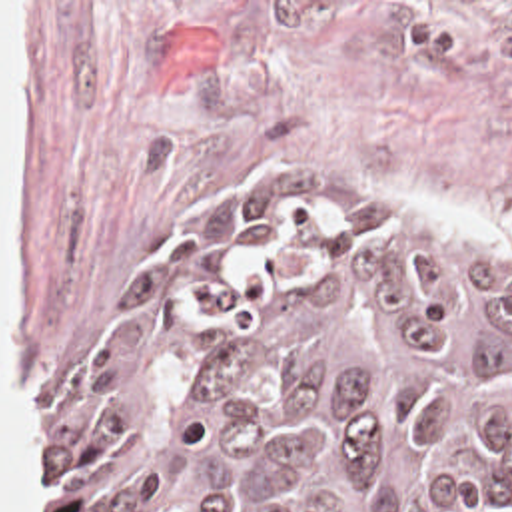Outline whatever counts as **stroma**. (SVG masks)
I'll return each mask as SVG.
<instances>
[{
  "label": "stroma",
  "instance_id": "35a3bbf8",
  "mask_svg": "<svg viewBox=\"0 0 512 512\" xmlns=\"http://www.w3.org/2000/svg\"><path fill=\"white\" fill-rule=\"evenodd\" d=\"M23 2V319L51 403L121 283L205 188L295 176L380 224L512 266L400 192L512 230V0ZM512 512V497L504 511Z\"/></svg>",
  "mask_w": 512,
  "mask_h": 512
}]
</instances>
